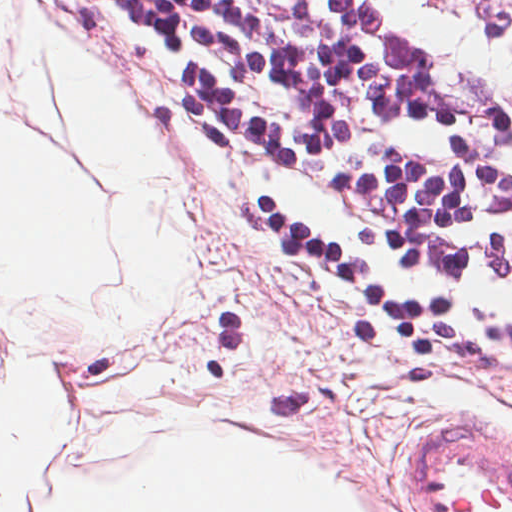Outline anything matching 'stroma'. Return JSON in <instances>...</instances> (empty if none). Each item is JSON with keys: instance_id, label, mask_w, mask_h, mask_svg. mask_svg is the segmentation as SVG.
I'll list each match as a JSON object with an SVG mask.
<instances>
[{"instance_id": "1", "label": "stroma", "mask_w": 512, "mask_h": 512, "mask_svg": "<svg viewBox=\"0 0 512 512\" xmlns=\"http://www.w3.org/2000/svg\"><path fill=\"white\" fill-rule=\"evenodd\" d=\"M41 17L59 30L82 71L123 98L175 184V238L186 258L171 311L147 329L128 316L93 338L53 310L0 292V347L12 315L54 343L66 362L268 403L499 453L442 405L439 388L364 291L316 249L279 239L227 195L170 101L130 49L103 37L74 0H9L11 59L0 74V129H56L26 89L25 61ZM90 190L114 248L120 220L89 166Z\"/></svg>"}]
</instances>
